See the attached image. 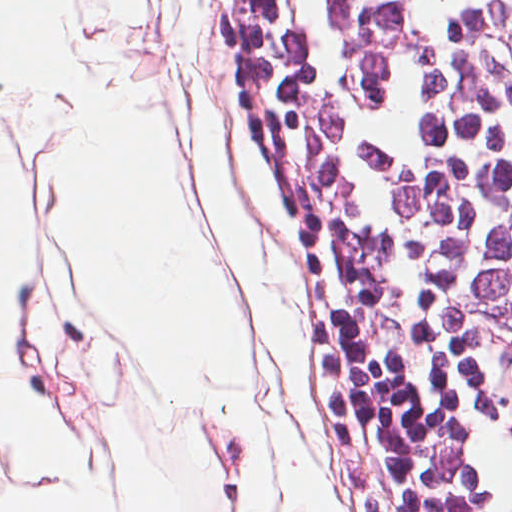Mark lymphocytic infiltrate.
Instances as JSON below:
<instances>
[{"instance_id":"obj_1","label":"lymphocytic infiltrate","mask_w":512,"mask_h":512,"mask_svg":"<svg viewBox=\"0 0 512 512\" xmlns=\"http://www.w3.org/2000/svg\"><path fill=\"white\" fill-rule=\"evenodd\" d=\"M463 512H512V0H354L304 235Z\"/></svg>"}]
</instances>
